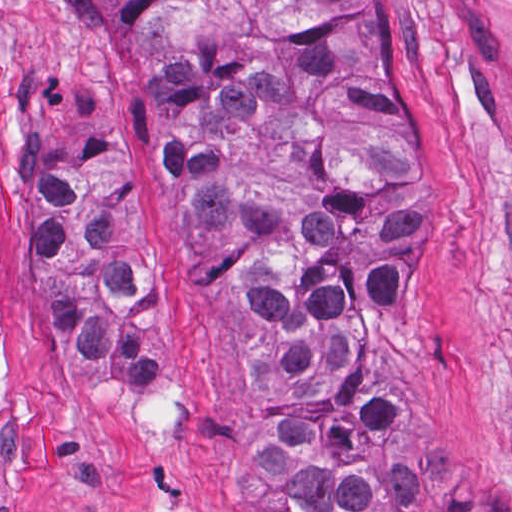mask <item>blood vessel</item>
<instances>
[{
  "instance_id": "1",
  "label": "blood vessel",
  "mask_w": 512,
  "mask_h": 512,
  "mask_svg": "<svg viewBox=\"0 0 512 512\" xmlns=\"http://www.w3.org/2000/svg\"><path fill=\"white\" fill-rule=\"evenodd\" d=\"M474 46L512 78V0H440Z\"/></svg>"
}]
</instances>
